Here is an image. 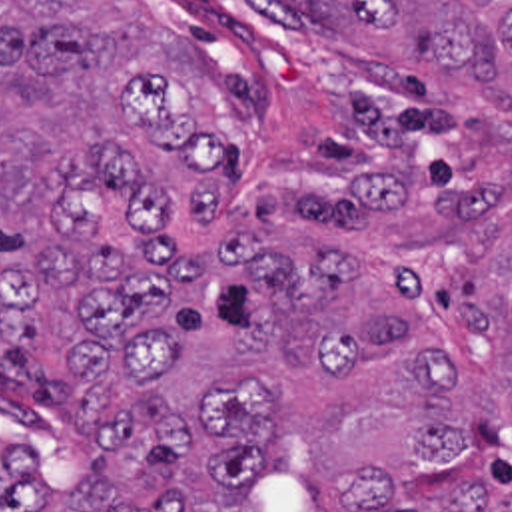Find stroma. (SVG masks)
<instances>
[{"label": "stroma", "instance_id": "stroma-1", "mask_svg": "<svg viewBox=\"0 0 512 512\" xmlns=\"http://www.w3.org/2000/svg\"><path fill=\"white\" fill-rule=\"evenodd\" d=\"M210 84L222 112L226 186L206 214H272L340 160L334 106L376 62L286 0H131ZM0 430L53 461L83 453V422L0 370Z\"/></svg>", "mask_w": 512, "mask_h": 512}]
</instances>
